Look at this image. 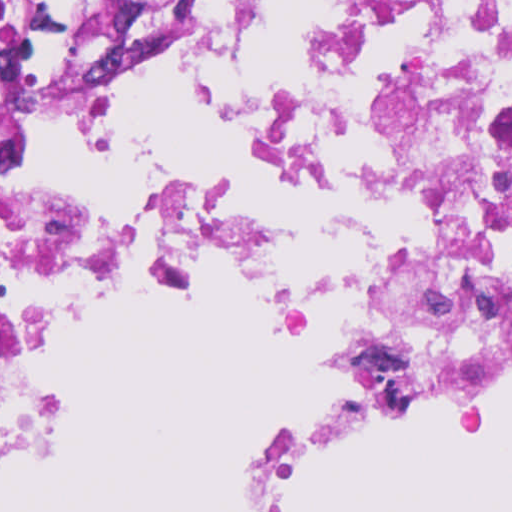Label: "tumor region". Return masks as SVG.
Here are the masks:
<instances>
[{
  "label": "tumor region",
  "mask_w": 512,
  "mask_h": 512,
  "mask_svg": "<svg viewBox=\"0 0 512 512\" xmlns=\"http://www.w3.org/2000/svg\"><path fill=\"white\" fill-rule=\"evenodd\" d=\"M186 12L187 0H0V89L57 82Z\"/></svg>",
  "instance_id": "tumor-region-1"
}]
</instances>
